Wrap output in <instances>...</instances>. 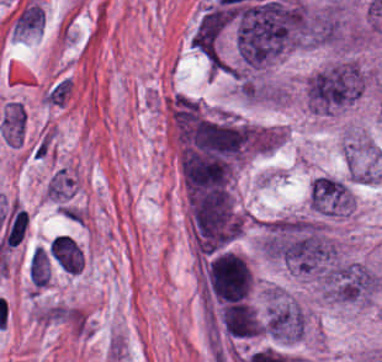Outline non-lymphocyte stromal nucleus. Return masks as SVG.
<instances>
[{
    "label": "non-lymphocyte stromal nucleus",
    "instance_id": "dd21d789",
    "mask_svg": "<svg viewBox=\"0 0 382 362\" xmlns=\"http://www.w3.org/2000/svg\"><path fill=\"white\" fill-rule=\"evenodd\" d=\"M53 259L60 268L69 273H78L83 266L82 249L68 236L57 235L50 243Z\"/></svg>",
    "mask_w": 382,
    "mask_h": 362
},
{
    "label": "non-lymphocyte stromal nucleus",
    "instance_id": "a72fc3eb",
    "mask_svg": "<svg viewBox=\"0 0 382 362\" xmlns=\"http://www.w3.org/2000/svg\"><path fill=\"white\" fill-rule=\"evenodd\" d=\"M33 317L37 322L77 324L79 314L72 306L67 305H47L33 312Z\"/></svg>",
    "mask_w": 382,
    "mask_h": 362
},
{
    "label": "non-lymphocyte stromal nucleus",
    "instance_id": "3746e769",
    "mask_svg": "<svg viewBox=\"0 0 382 362\" xmlns=\"http://www.w3.org/2000/svg\"><path fill=\"white\" fill-rule=\"evenodd\" d=\"M30 280L39 288H46L51 276V267L41 248L35 247L28 265Z\"/></svg>",
    "mask_w": 382,
    "mask_h": 362
}]
</instances>
